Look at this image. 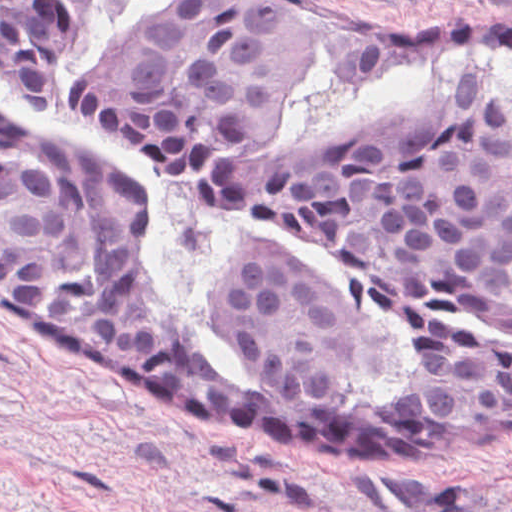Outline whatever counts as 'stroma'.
Masks as SVG:
<instances>
[{"label": "stroma", "instance_id": "1", "mask_svg": "<svg viewBox=\"0 0 512 512\" xmlns=\"http://www.w3.org/2000/svg\"><path fill=\"white\" fill-rule=\"evenodd\" d=\"M358 36L512 0H269ZM0 512H512V430H357L239 402L0 297Z\"/></svg>", "mask_w": 512, "mask_h": 512}]
</instances>
